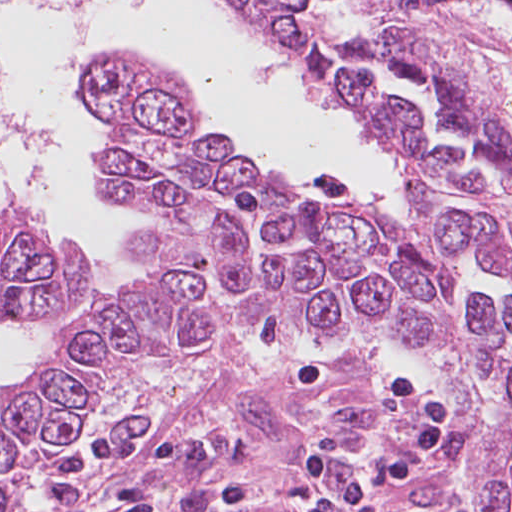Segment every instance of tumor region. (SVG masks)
<instances>
[{"instance_id":"obj_1","label":"tumor region","mask_w":512,"mask_h":512,"mask_svg":"<svg viewBox=\"0 0 512 512\" xmlns=\"http://www.w3.org/2000/svg\"><path fill=\"white\" fill-rule=\"evenodd\" d=\"M404 173L408 209L305 197L228 154L206 115L125 56L86 80L108 190L153 222L137 287L71 321L22 378L43 450L100 385L167 351L401 337L477 413L485 512H512V110L412 31L403 0H213ZM82 250L0 213V316L74 304Z\"/></svg>"}]
</instances>
